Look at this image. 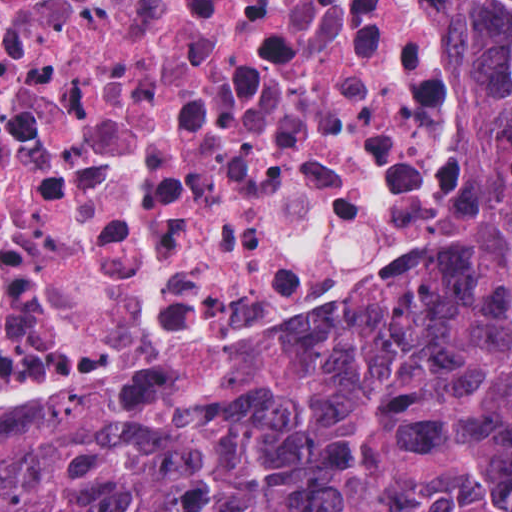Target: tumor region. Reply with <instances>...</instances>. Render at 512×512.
Returning a JSON list of instances; mask_svg holds the SVG:
<instances>
[{
	"label": "tumor region",
	"instance_id": "e687c5a6",
	"mask_svg": "<svg viewBox=\"0 0 512 512\" xmlns=\"http://www.w3.org/2000/svg\"><path fill=\"white\" fill-rule=\"evenodd\" d=\"M512 140V0H459ZM0 512H512V280L300 327L167 394L0 433Z\"/></svg>",
	"mask_w": 512,
	"mask_h": 512
}]
</instances>
